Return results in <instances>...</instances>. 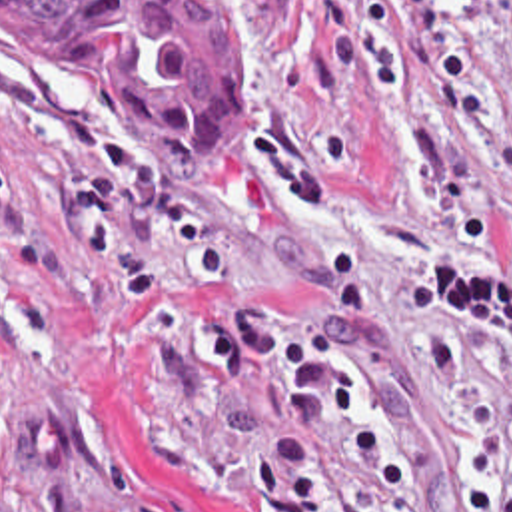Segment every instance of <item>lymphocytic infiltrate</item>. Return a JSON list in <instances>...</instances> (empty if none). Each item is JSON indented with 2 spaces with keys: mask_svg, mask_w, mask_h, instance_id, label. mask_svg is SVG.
Instances as JSON below:
<instances>
[{
  "mask_svg": "<svg viewBox=\"0 0 512 512\" xmlns=\"http://www.w3.org/2000/svg\"><path fill=\"white\" fill-rule=\"evenodd\" d=\"M419 0H347L321 40L329 68L363 76L391 94L403 90L399 44L415 68L443 88L461 117L483 112V84L471 74L469 50L453 22ZM495 6L501 0H471ZM501 171L512 185V133L501 137ZM453 229L473 243L503 245L497 285L477 281L465 259L423 263L405 283L427 309L455 331L512 329V213L493 217L483 207H447ZM321 291L311 327H281L255 293L233 297L225 317L190 323L188 341L213 379H257L273 391V421L247 445L237 489L253 512L317 511L319 483L311 469L317 427L343 449L365 453L369 507L389 512L407 483L383 429L365 413V261L347 229L317 241ZM423 353L467 419L463 449L465 512H512V407L477 395L449 341L429 337Z\"/></svg>",
  "mask_w": 512,
  "mask_h": 512,
  "instance_id": "lymphocytic-infiltrate-1",
  "label": "lymphocytic infiltrate"
}]
</instances>
